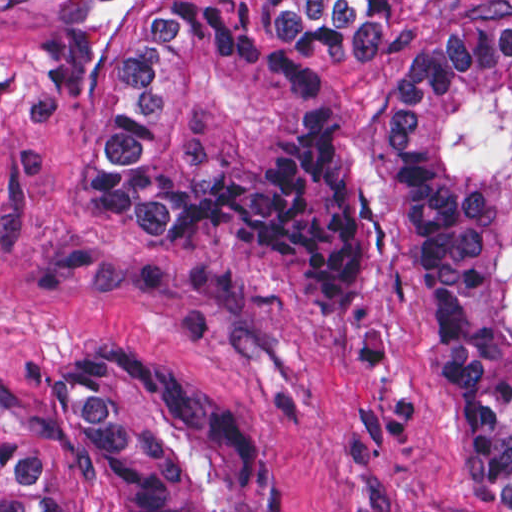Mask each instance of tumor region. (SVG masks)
Here are the masks:
<instances>
[{
	"label": "tumor region",
	"instance_id": "1",
	"mask_svg": "<svg viewBox=\"0 0 512 512\" xmlns=\"http://www.w3.org/2000/svg\"><path fill=\"white\" fill-rule=\"evenodd\" d=\"M393 2L431 33L405 53L386 160L430 305L445 462L512 512V1H57L48 80L87 109L77 199L148 240L272 244L318 319H358L367 270L320 61L374 72ZM283 498L245 412L164 346L103 341L1 424V512H247Z\"/></svg>",
	"mask_w": 512,
	"mask_h": 512
}]
</instances>
